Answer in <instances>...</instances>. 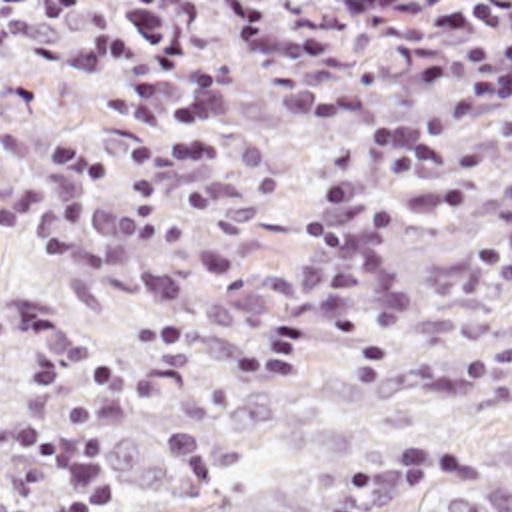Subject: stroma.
Wrapping results in <instances>:
<instances>
[{
    "instance_id": "obj_1",
    "label": "stroma",
    "mask_w": 512,
    "mask_h": 512,
    "mask_svg": "<svg viewBox=\"0 0 512 512\" xmlns=\"http://www.w3.org/2000/svg\"><path fill=\"white\" fill-rule=\"evenodd\" d=\"M512 349V0H0V405Z\"/></svg>"
}]
</instances>
